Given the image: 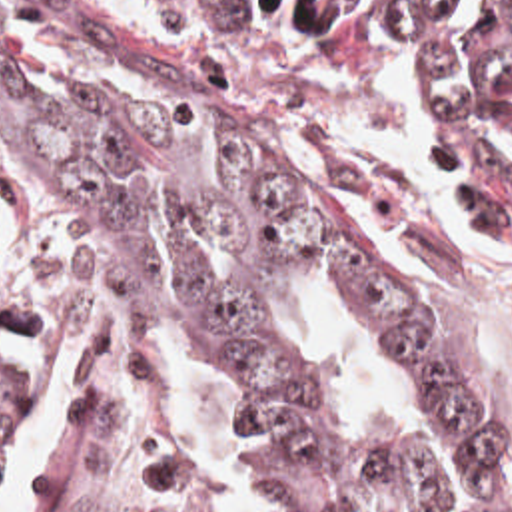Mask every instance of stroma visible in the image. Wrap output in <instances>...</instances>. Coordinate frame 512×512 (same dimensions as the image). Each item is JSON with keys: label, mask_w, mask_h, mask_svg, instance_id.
Returning a JSON list of instances; mask_svg holds the SVG:
<instances>
[{"label": "stroma", "mask_w": 512, "mask_h": 512, "mask_svg": "<svg viewBox=\"0 0 512 512\" xmlns=\"http://www.w3.org/2000/svg\"><path fill=\"white\" fill-rule=\"evenodd\" d=\"M0 23L61 31L332 153L374 203L442 347L512 447V265L414 133L408 51L418 33L236 27L178 0H0Z\"/></svg>", "instance_id": "stroma-1"}]
</instances>
